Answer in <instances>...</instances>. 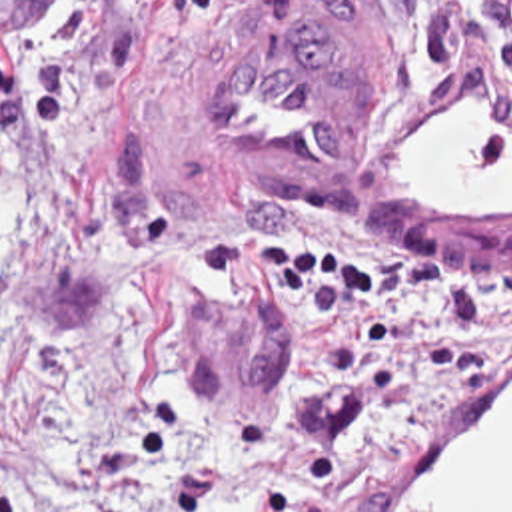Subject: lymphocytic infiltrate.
Returning a JSON list of instances; mask_svg holds the SVG:
<instances>
[{
    "label": "lymphocytic infiltrate",
    "mask_w": 512,
    "mask_h": 512,
    "mask_svg": "<svg viewBox=\"0 0 512 512\" xmlns=\"http://www.w3.org/2000/svg\"><path fill=\"white\" fill-rule=\"evenodd\" d=\"M206 0H72L50 52L0 72V114L46 146L78 138L138 76L146 18ZM379 18L431 76H457L487 34L489 84L512 154V0H345ZM186 293L337 301L357 347L401 367L461 371L512 321V258L441 266L369 234H248L194 250Z\"/></svg>",
    "instance_id": "obj_1"
}]
</instances>
